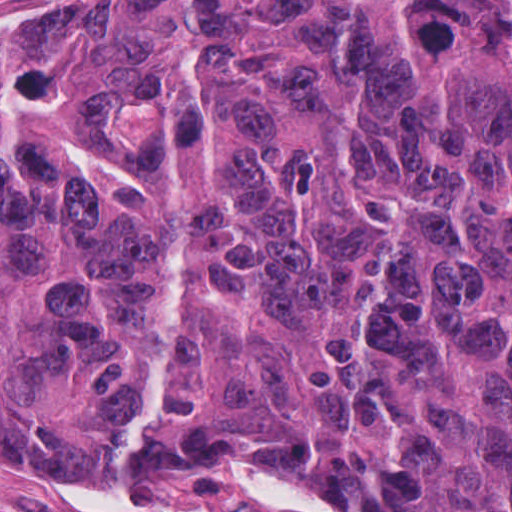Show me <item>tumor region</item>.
Returning a JSON list of instances; mask_svg holds the SVG:
<instances>
[{
  "instance_id": "e687c5a6",
  "label": "tumor region",
  "mask_w": 512,
  "mask_h": 512,
  "mask_svg": "<svg viewBox=\"0 0 512 512\" xmlns=\"http://www.w3.org/2000/svg\"><path fill=\"white\" fill-rule=\"evenodd\" d=\"M204 451L512 512V0H122L0 65V460Z\"/></svg>"
}]
</instances>
